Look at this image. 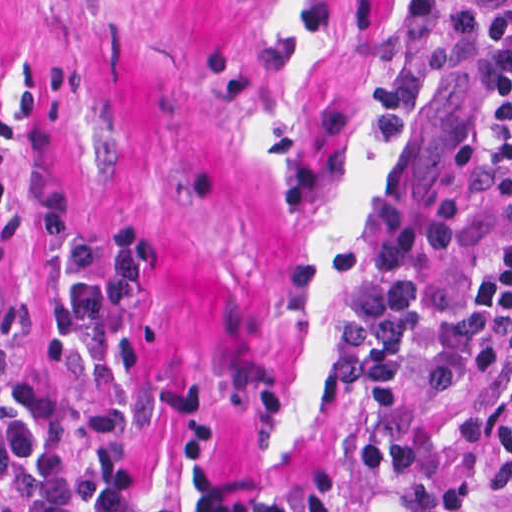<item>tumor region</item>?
Listing matches in <instances>:
<instances>
[{"label": "tumor region", "mask_w": 512, "mask_h": 512, "mask_svg": "<svg viewBox=\"0 0 512 512\" xmlns=\"http://www.w3.org/2000/svg\"><path fill=\"white\" fill-rule=\"evenodd\" d=\"M433 498L445 512H512V370L435 429Z\"/></svg>", "instance_id": "e687c5a6"}]
</instances>
